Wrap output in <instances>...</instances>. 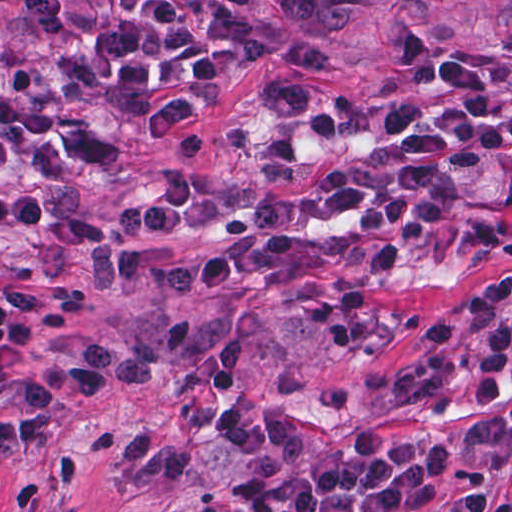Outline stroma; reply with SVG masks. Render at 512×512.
Instances as JSON below:
<instances>
[{
  "instance_id": "stroma-1",
  "label": "stroma",
  "mask_w": 512,
  "mask_h": 512,
  "mask_svg": "<svg viewBox=\"0 0 512 512\" xmlns=\"http://www.w3.org/2000/svg\"><path fill=\"white\" fill-rule=\"evenodd\" d=\"M246 36L252 65L219 95L155 121L98 120L106 154L91 175L12 190L66 213H111L156 179L187 172L215 193L220 145L277 79L320 83L331 117L297 164L261 200L350 157L384 149L355 134L361 118L410 79L429 76L456 49L512 47V0H207ZM0 0V60L25 63L33 36ZM289 231L356 248L396 251L405 286L389 294V350L352 353L288 294L229 289L186 301L144 298L99 270L31 240H6L0 303L9 288L88 301L56 334L36 324L31 365L85 359L102 343L152 365V383L119 386L98 401L60 406L41 443L0 458V512H246L233 427L271 420L308 436L318 456L348 452L353 433L449 444L434 505L483 487L512 497V368L505 410L481 402L465 350L430 352L423 325L501 269L512 268V152L485 159L453 233L419 246L369 236L350 223L279 225L234 217L210 232L258 237ZM512 319V303L502 311ZM3 394L0 390V402ZM512 512V511H511Z\"/></svg>"
}]
</instances>
